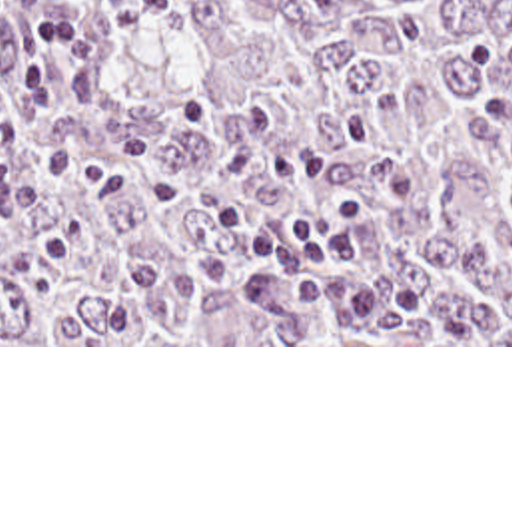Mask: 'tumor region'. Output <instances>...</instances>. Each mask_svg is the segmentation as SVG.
I'll use <instances>...</instances> for the list:
<instances>
[{
    "label": "tumor region",
    "mask_w": 512,
    "mask_h": 512,
    "mask_svg": "<svg viewBox=\"0 0 512 512\" xmlns=\"http://www.w3.org/2000/svg\"><path fill=\"white\" fill-rule=\"evenodd\" d=\"M0 0V91L31 18ZM91 42L0 151V345H512V0H77ZM371 201L327 271L415 285L389 325L249 299L233 205Z\"/></svg>",
    "instance_id": "tumor-region-1"
}]
</instances>
